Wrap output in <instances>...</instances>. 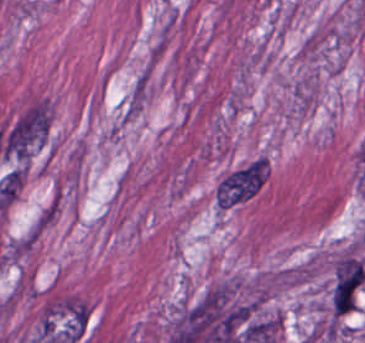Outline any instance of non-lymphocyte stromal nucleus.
Masks as SVG:
<instances>
[{"mask_svg": "<svg viewBox=\"0 0 365 343\" xmlns=\"http://www.w3.org/2000/svg\"><path fill=\"white\" fill-rule=\"evenodd\" d=\"M267 176V163L256 159L222 179L216 190V203L230 207L250 198L263 185Z\"/></svg>", "mask_w": 365, "mask_h": 343, "instance_id": "non-lymphocyte-stromal-nucleus-2", "label": "non-lymphocyte stromal nucleus"}, {"mask_svg": "<svg viewBox=\"0 0 365 343\" xmlns=\"http://www.w3.org/2000/svg\"><path fill=\"white\" fill-rule=\"evenodd\" d=\"M48 122L45 106H31L8 127L0 149L4 154L26 160L42 143Z\"/></svg>", "mask_w": 365, "mask_h": 343, "instance_id": "non-lymphocyte-stromal-nucleus-1", "label": "non-lymphocyte stromal nucleus"}]
</instances>
